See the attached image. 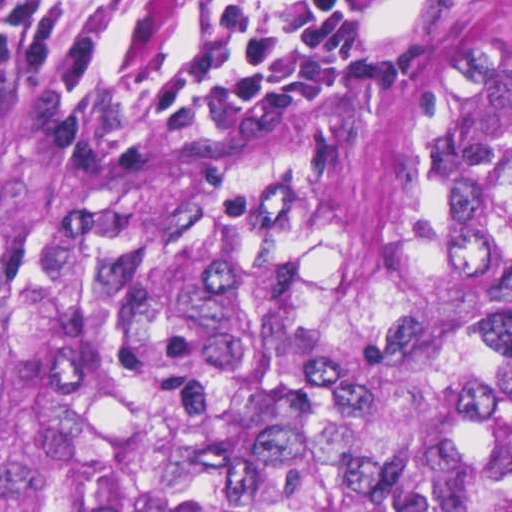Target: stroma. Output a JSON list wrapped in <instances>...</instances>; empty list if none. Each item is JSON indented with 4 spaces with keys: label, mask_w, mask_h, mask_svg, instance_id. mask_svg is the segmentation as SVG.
<instances>
[{
    "label": "stroma",
    "mask_w": 512,
    "mask_h": 512,
    "mask_svg": "<svg viewBox=\"0 0 512 512\" xmlns=\"http://www.w3.org/2000/svg\"><path fill=\"white\" fill-rule=\"evenodd\" d=\"M458 0H371L350 48L274 103H187L108 94L0 68L8 89L125 119L199 128H349L382 121L427 43Z\"/></svg>",
    "instance_id": "obj_1"
}]
</instances>
